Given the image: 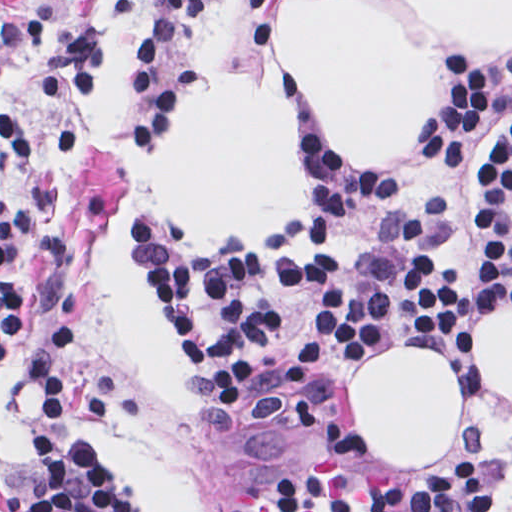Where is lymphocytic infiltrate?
Instances as JSON below:
<instances>
[{"mask_svg": "<svg viewBox=\"0 0 512 512\" xmlns=\"http://www.w3.org/2000/svg\"><path fill=\"white\" fill-rule=\"evenodd\" d=\"M31 39L43 49L45 94L76 100L99 83L104 38L96 27L64 31L40 15L0 24V57ZM495 106L512 109V76L450 61L420 158L403 177L337 174L322 152L318 193L291 236L247 248L144 252L140 274L152 300L262 434H284L301 422L341 357L376 333L401 324L463 332L478 316L512 304V123L471 191L484 256L480 277L444 262L427 228L399 212L376 221L348 255L299 260L283 253V241L291 238H334L349 216L404 190L420 171H455ZM26 154L17 124L0 113V169ZM51 231L45 196L36 188L9 197L0 211V353L20 303L22 249ZM80 336L81 321L63 317L31 357L36 484L25 507L136 512L75 420ZM311 431L276 462L249 512H484L479 453L442 451L415 483H349L330 475ZM506 467L512 476V420Z\"/></svg>", "mask_w": 512, "mask_h": 512, "instance_id": "obj_1", "label": "lymphocytic infiltrate"}]
</instances>
